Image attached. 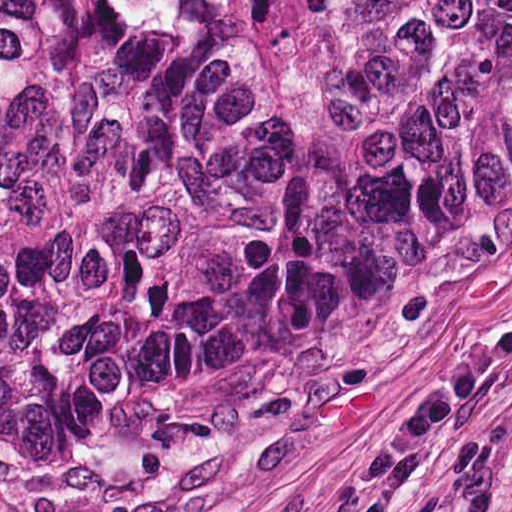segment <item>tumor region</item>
<instances>
[{
    "label": "tumor region",
    "mask_w": 512,
    "mask_h": 512,
    "mask_svg": "<svg viewBox=\"0 0 512 512\" xmlns=\"http://www.w3.org/2000/svg\"><path fill=\"white\" fill-rule=\"evenodd\" d=\"M512 141V0H0V457L342 304Z\"/></svg>",
    "instance_id": "1"
}]
</instances>
